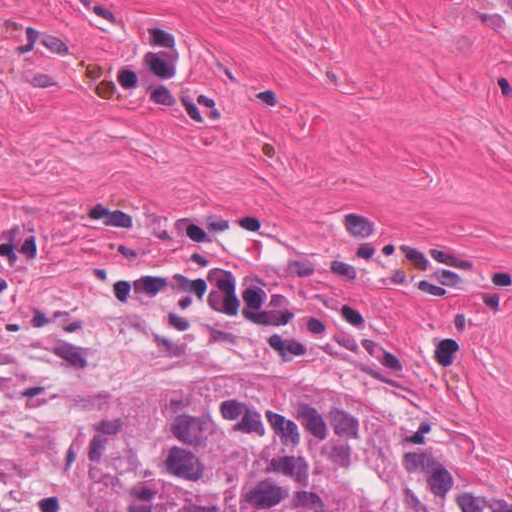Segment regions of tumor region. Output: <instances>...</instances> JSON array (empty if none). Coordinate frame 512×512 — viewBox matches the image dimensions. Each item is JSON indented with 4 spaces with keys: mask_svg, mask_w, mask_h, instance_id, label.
<instances>
[{
    "mask_svg": "<svg viewBox=\"0 0 512 512\" xmlns=\"http://www.w3.org/2000/svg\"><path fill=\"white\" fill-rule=\"evenodd\" d=\"M0 512H28L0 500ZM74 512H512L406 426L295 384H159L96 415Z\"/></svg>",
    "mask_w": 512,
    "mask_h": 512,
    "instance_id": "tumor-region-1",
    "label": "tumor region"
}]
</instances>
